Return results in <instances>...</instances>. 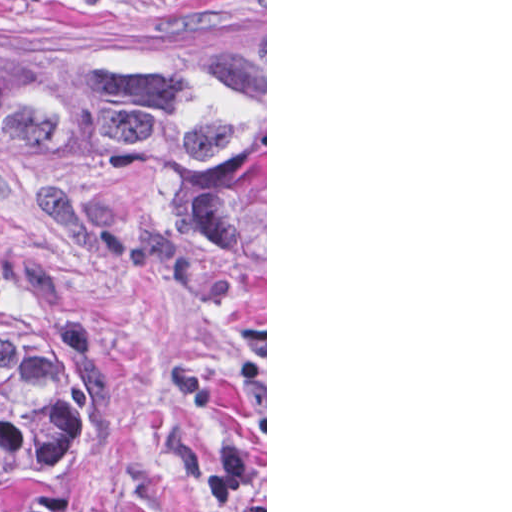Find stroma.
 Wrapping results in <instances>:
<instances>
[{"label": "stroma", "mask_w": 512, "mask_h": 512, "mask_svg": "<svg viewBox=\"0 0 512 512\" xmlns=\"http://www.w3.org/2000/svg\"><path fill=\"white\" fill-rule=\"evenodd\" d=\"M265 36V338L205 282L92 244L0 193V329L74 374L76 512H267V0H0V52L218 58Z\"/></svg>", "instance_id": "1"}]
</instances>
